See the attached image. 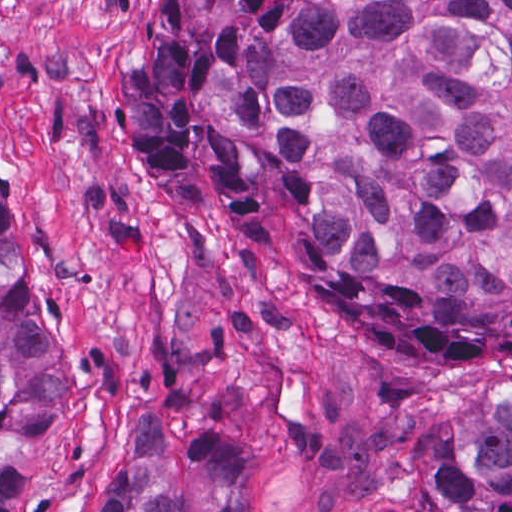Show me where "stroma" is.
<instances>
[{
  "label": "stroma",
  "mask_w": 512,
  "mask_h": 512,
  "mask_svg": "<svg viewBox=\"0 0 512 512\" xmlns=\"http://www.w3.org/2000/svg\"><path fill=\"white\" fill-rule=\"evenodd\" d=\"M160 0H0L1 204L62 405L38 512H107L145 409L232 442L251 512H425L434 473L512 396V359L369 339L296 254L279 175L263 237L210 158L154 181L127 114Z\"/></svg>",
  "instance_id": "stroma-1"
}]
</instances>
